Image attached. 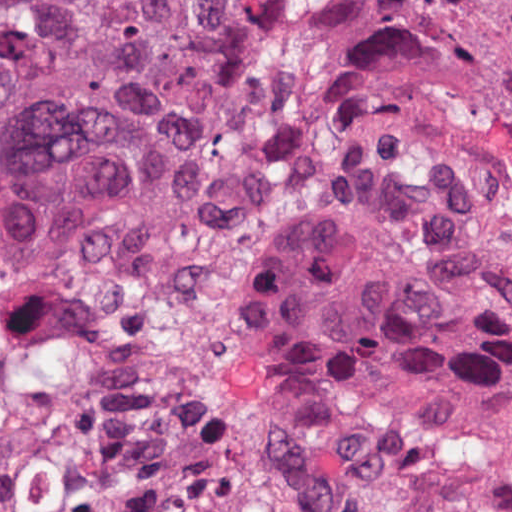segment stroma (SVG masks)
Instances as JSON below:
<instances>
[{
    "label": "stroma",
    "mask_w": 512,
    "mask_h": 512,
    "mask_svg": "<svg viewBox=\"0 0 512 512\" xmlns=\"http://www.w3.org/2000/svg\"><path fill=\"white\" fill-rule=\"evenodd\" d=\"M404 132L397 112L377 108L326 149L269 176L236 201L169 222L149 234L58 255L103 251L183 223H213L268 195L295 189L313 193L311 207L283 236L249 297L243 324L247 376L255 335L278 290L308 251L379 182ZM32 263L20 266L0 259V272ZM256 419L264 457L304 488L330 500L397 512H512V442L424 436L369 448L294 435L276 425L257 401Z\"/></svg>",
    "instance_id": "1"
}]
</instances>
